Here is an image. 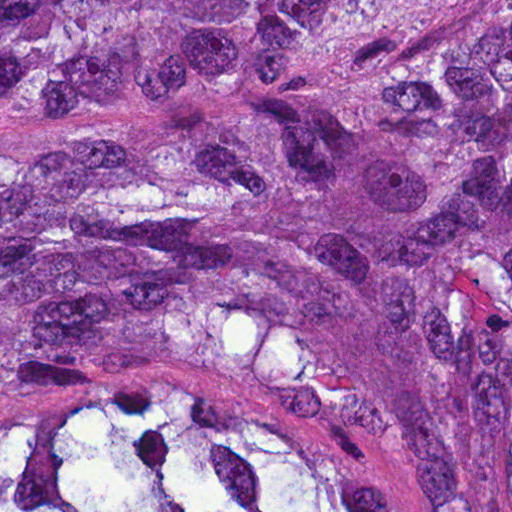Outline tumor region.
Returning <instances> with one entry per match:
<instances>
[{
    "instance_id": "obj_1",
    "label": "tumor region",
    "mask_w": 512,
    "mask_h": 512,
    "mask_svg": "<svg viewBox=\"0 0 512 512\" xmlns=\"http://www.w3.org/2000/svg\"><path fill=\"white\" fill-rule=\"evenodd\" d=\"M0 512H512V0H0Z\"/></svg>"
}]
</instances>
